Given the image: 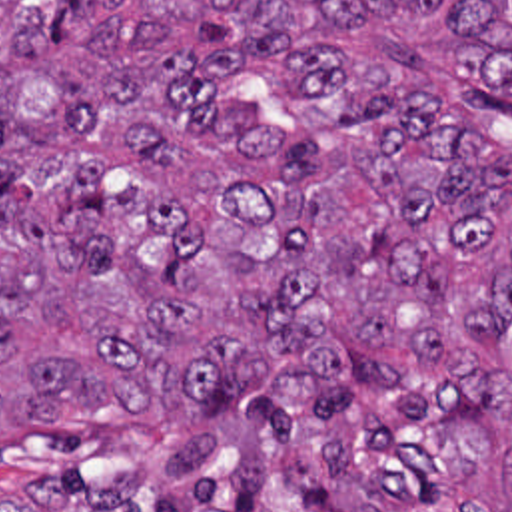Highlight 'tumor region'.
I'll return each mask as SVG.
<instances>
[{
	"label": "tumor region",
	"instance_id": "1",
	"mask_svg": "<svg viewBox=\"0 0 512 512\" xmlns=\"http://www.w3.org/2000/svg\"><path fill=\"white\" fill-rule=\"evenodd\" d=\"M510 117L512 0H0V512H512Z\"/></svg>",
	"mask_w": 512,
	"mask_h": 512
}]
</instances>
